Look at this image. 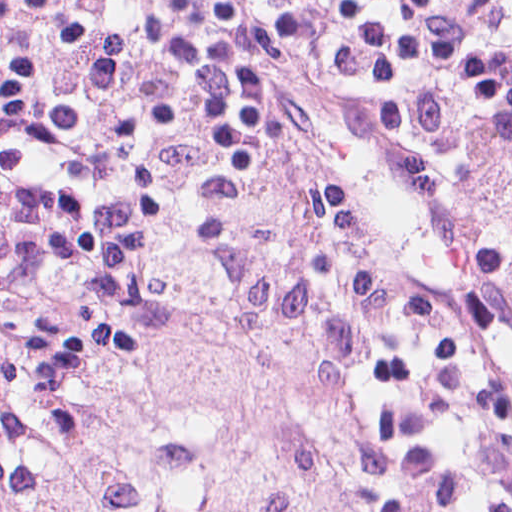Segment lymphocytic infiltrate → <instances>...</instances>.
<instances>
[{
    "label": "lymphocytic infiltrate",
    "instance_id": "lymphocytic-infiltrate-1",
    "mask_svg": "<svg viewBox=\"0 0 512 512\" xmlns=\"http://www.w3.org/2000/svg\"><path fill=\"white\" fill-rule=\"evenodd\" d=\"M381 129L444 211L512 273V0H431L426 86L403 91L316 60L297 76ZM267 126L241 142L271 137ZM171 210L103 263L0 278V319L38 363L93 350L152 304L173 263Z\"/></svg>",
    "mask_w": 512,
    "mask_h": 512
}]
</instances>
